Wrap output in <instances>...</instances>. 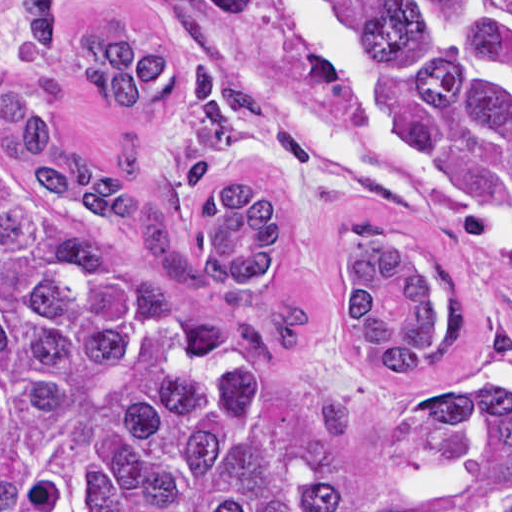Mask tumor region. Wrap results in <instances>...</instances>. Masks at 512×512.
I'll return each mask as SVG.
<instances>
[{
	"label": "tumor region",
	"instance_id": "obj_1",
	"mask_svg": "<svg viewBox=\"0 0 512 512\" xmlns=\"http://www.w3.org/2000/svg\"><path fill=\"white\" fill-rule=\"evenodd\" d=\"M360 39L383 109L435 196L426 235L356 256L341 327L421 430L485 465L512 512V394L449 270L475 235L512 238V112L461 59L512 70V0H319ZM64 0H21L36 59L121 113L178 94L187 140L161 182L190 189L237 147L261 99L143 40L57 39ZM61 79L0 92V512H374L298 428L262 350L304 345L309 305L267 293L278 203L210 194L198 260L172 240L131 131L105 165L60 141ZM135 232L140 250L90 217Z\"/></svg>",
	"mask_w": 512,
	"mask_h": 512
}]
</instances>
